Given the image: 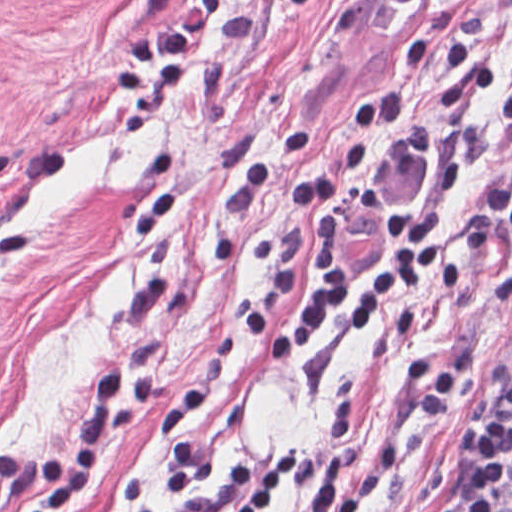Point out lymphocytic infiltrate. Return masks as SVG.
Returning <instances> with one entry per match:
<instances>
[{
    "label": "lymphocytic infiltrate",
    "mask_w": 512,
    "mask_h": 512,
    "mask_svg": "<svg viewBox=\"0 0 512 512\" xmlns=\"http://www.w3.org/2000/svg\"><path fill=\"white\" fill-rule=\"evenodd\" d=\"M487 213L512 232V174L494 185ZM445 215L433 209L390 211L382 263L362 274L324 270L312 294L282 318H271L299 287L301 270L259 292L250 310L233 321L236 338L256 354H283L312 338L320 321L341 314L359 333L381 329L384 309L395 296H421L430 288L459 291L458 240L446 230ZM156 399L155 373L148 364L111 365L94 373L87 400L60 457L0 454L2 486L20 497L12 512H58L72 497L78 479L97 476L106 466L115 420L146 421ZM303 461L292 444L274 454L247 457L235 467L218 497L184 501L179 512H263ZM512 489V380L472 452L462 480L444 512H497ZM145 498L135 512H167Z\"/></svg>",
    "instance_id": "obj_1"
}]
</instances>
